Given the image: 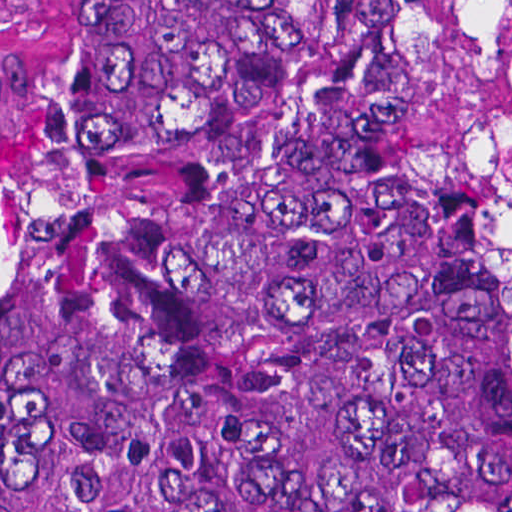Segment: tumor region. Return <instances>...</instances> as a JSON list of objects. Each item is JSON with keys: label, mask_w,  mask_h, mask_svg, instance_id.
Segmentation results:
<instances>
[{"label": "tumor region", "mask_w": 512, "mask_h": 512, "mask_svg": "<svg viewBox=\"0 0 512 512\" xmlns=\"http://www.w3.org/2000/svg\"><path fill=\"white\" fill-rule=\"evenodd\" d=\"M62 3L0 512H512V0Z\"/></svg>", "instance_id": "tumor-region-1"}]
</instances>
